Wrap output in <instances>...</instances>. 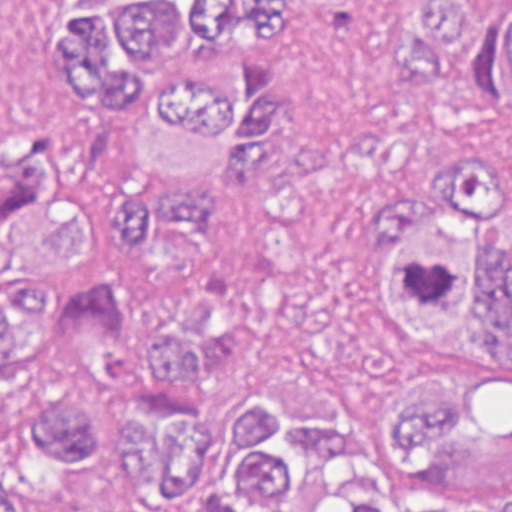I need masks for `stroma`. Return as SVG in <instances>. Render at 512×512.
<instances>
[{
    "mask_svg": "<svg viewBox=\"0 0 512 512\" xmlns=\"http://www.w3.org/2000/svg\"><path fill=\"white\" fill-rule=\"evenodd\" d=\"M407 0H276L265 33L283 82L282 113L241 172H221L196 232L155 228L140 244L97 229L80 240L95 279L132 307L125 345L97 379L96 446L82 460H43L0 422V476L25 512H177L135 494L120 437L126 357L162 313L194 297L312 261L345 242L353 211L414 167L435 137L429 101L392 59ZM314 363L367 442L386 438L397 387L352 324L289 335L260 369Z\"/></svg>",
    "mask_w": 512,
    "mask_h": 512,
    "instance_id": "1",
    "label": "stroma"
}]
</instances>
